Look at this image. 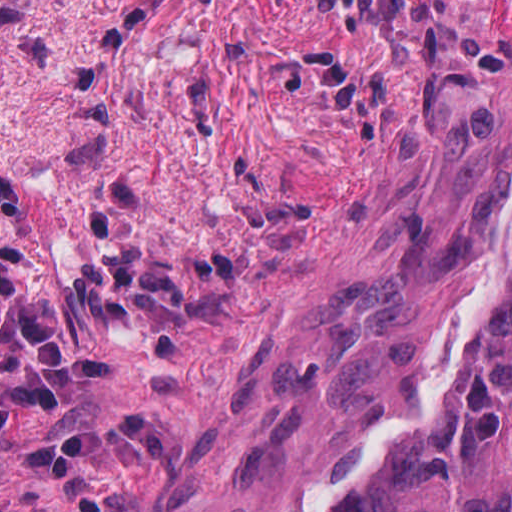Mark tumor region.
<instances>
[{"instance_id":"1","label":"tumor region","mask_w":512,"mask_h":512,"mask_svg":"<svg viewBox=\"0 0 512 512\" xmlns=\"http://www.w3.org/2000/svg\"><path fill=\"white\" fill-rule=\"evenodd\" d=\"M220 512H512V246L484 299Z\"/></svg>"}]
</instances>
